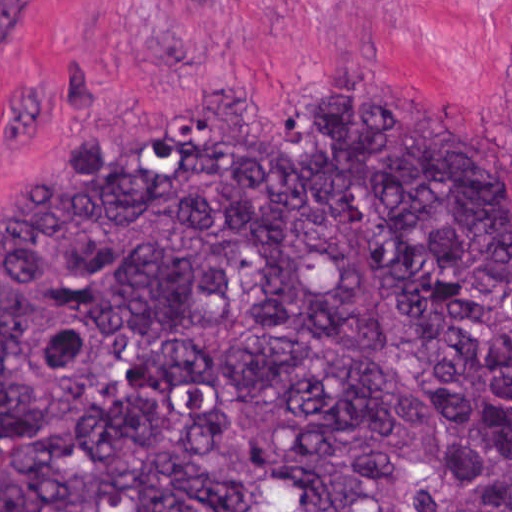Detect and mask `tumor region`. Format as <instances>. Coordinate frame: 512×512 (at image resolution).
I'll return each instance as SVG.
<instances>
[{
  "label": "tumor region",
  "mask_w": 512,
  "mask_h": 512,
  "mask_svg": "<svg viewBox=\"0 0 512 512\" xmlns=\"http://www.w3.org/2000/svg\"><path fill=\"white\" fill-rule=\"evenodd\" d=\"M296 87L0 212V512H512V182L421 93Z\"/></svg>",
  "instance_id": "obj_1"
}]
</instances>
